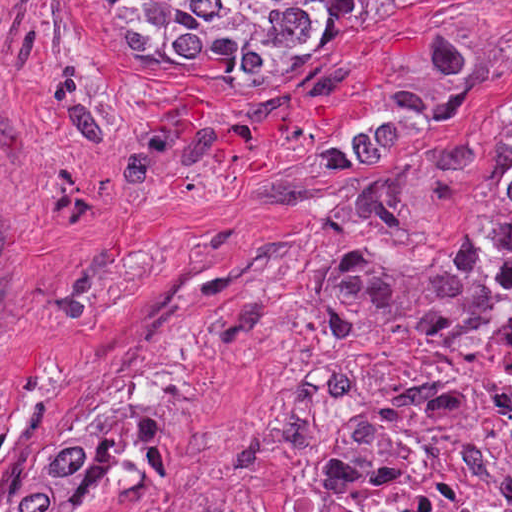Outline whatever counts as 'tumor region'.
I'll return each mask as SVG.
<instances>
[{
	"instance_id": "obj_1",
	"label": "tumor region",
	"mask_w": 512,
	"mask_h": 512,
	"mask_svg": "<svg viewBox=\"0 0 512 512\" xmlns=\"http://www.w3.org/2000/svg\"><path fill=\"white\" fill-rule=\"evenodd\" d=\"M435 1L97 0V31L121 35L132 70L254 80L326 62L368 12ZM319 300L341 338L413 382L353 417L288 512H512V120L492 195L438 250L343 244ZM110 458L109 437H92L25 471L0 465V507L73 512Z\"/></svg>"
}]
</instances>
